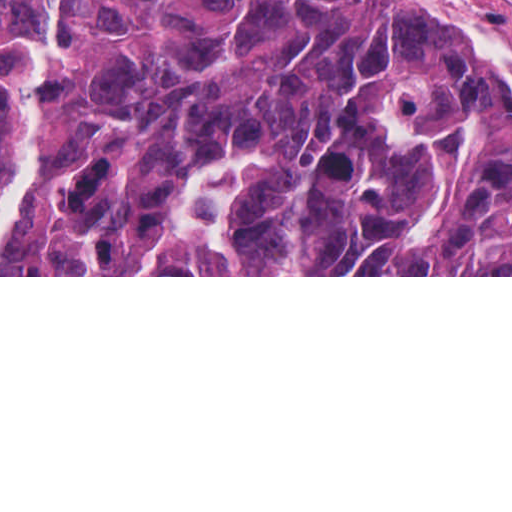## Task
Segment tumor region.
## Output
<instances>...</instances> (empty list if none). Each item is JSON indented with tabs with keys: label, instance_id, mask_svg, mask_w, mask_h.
<instances>
[{
	"label": "tumor region",
	"instance_id": "obj_1",
	"mask_svg": "<svg viewBox=\"0 0 512 512\" xmlns=\"http://www.w3.org/2000/svg\"><path fill=\"white\" fill-rule=\"evenodd\" d=\"M54 11L9 275H133L186 184L245 152L194 275H512V91L411 0H0V197Z\"/></svg>",
	"mask_w": 512,
	"mask_h": 512
}]
</instances>
